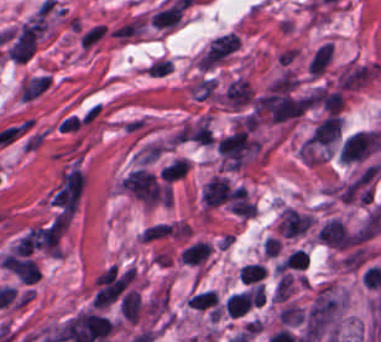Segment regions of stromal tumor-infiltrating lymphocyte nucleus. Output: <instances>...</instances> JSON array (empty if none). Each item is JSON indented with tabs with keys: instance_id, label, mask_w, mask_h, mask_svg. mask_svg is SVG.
<instances>
[{
	"instance_id": "stromal-tumor-infiltrating-lymphocyte-nucleus-1",
	"label": "stromal tumor-infiltrating lymphocyte nucleus",
	"mask_w": 381,
	"mask_h": 342,
	"mask_svg": "<svg viewBox=\"0 0 381 342\" xmlns=\"http://www.w3.org/2000/svg\"><path fill=\"white\" fill-rule=\"evenodd\" d=\"M224 99L233 109L248 106L253 99V88L243 77L233 79L224 91Z\"/></svg>"
},
{
	"instance_id": "stromal-tumor-infiltrating-lymphocyte-nucleus-2",
	"label": "stromal tumor-infiltrating lymphocyte nucleus",
	"mask_w": 381,
	"mask_h": 342,
	"mask_svg": "<svg viewBox=\"0 0 381 342\" xmlns=\"http://www.w3.org/2000/svg\"><path fill=\"white\" fill-rule=\"evenodd\" d=\"M231 188L227 177L214 175L202 191V199L207 207H216L227 201Z\"/></svg>"
},
{
	"instance_id": "stromal-tumor-infiltrating-lymphocyte-nucleus-3",
	"label": "stromal tumor-infiltrating lymphocyte nucleus",
	"mask_w": 381,
	"mask_h": 342,
	"mask_svg": "<svg viewBox=\"0 0 381 342\" xmlns=\"http://www.w3.org/2000/svg\"><path fill=\"white\" fill-rule=\"evenodd\" d=\"M119 311L125 319L135 324L140 311L139 292L131 289L126 293L119 304Z\"/></svg>"
},
{
	"instance_id": "stromal-tumor-infiltrating-lymphocyte-nucleus-4",
	"label": "stromal tumor-infiltrating lymphocyte nucleus",
	"mask_w": 381,
	"mask_h": 342,
	"mask_svg": "<svg viewBox=\"0 0 381 342\" xmlns=\"http://www.w3.org/2000/svg\"><path fill=\"white\" fill-rule=\"evenodd\" d=\"M210 249L207 242L196 241L184 248L180 258L185 264H201L208 256Z\"/></svg>"
},
{
	"instance_id": "stromal-tumor-infiltrating-lymphocyte-nucleus-5",
	"label": "stromal tumor-infiltrating lymphocyte nucleus",
	"mask_w": 381,
	"mask_h": 342,
	"mask_svg": "<svg viewBox=\"0 0 381 342\" xmlns=\"http://www.w3.org/2000/svg\"><path fill=\"white\" fill-rule=\"evenodd\" d=\"M334 48L331 44H324L310 61V75L319 76L328 67L333 57Z\"/></svg>"
},
{
	"instance_id": "stromal-tumor-infiltrating-lymphocyte-nucleus-6",
	"label": "stromal tumor-infiltrating lymphocyte nucleus",
	"mask_w": 381,
	"mask_h": 342,
	"mask_svg": "<svg viewBox=\"0 0 381 342\" xmlns=\"http://www.w3.org/2000/svg\"><path fill=\"white\" fill-rule=\"evenodd\" d=\"M189 166V159L184 157H176L160 169L159 175L163 180L171 182L177 178L184 176Z\"/></svg>"
},
{
	"instance_id": "stromal-tumor-infiltrating-lymphocyte-nucleus-7",
	"label": "stromal tumor-infiltrating lymphocyte nucleus",
	"mask_w": 381,
	"mask_h": 342,
	"mask_svg": "<svg viewBox=\"0 0 381 342\" xmlns=\"http://www.w3.org/2000/svg\"><path fill=\"white\" fill-rule=\"evenodd\" d=\"M196 310H205L218 303V294L212 289L194 293L186 302Z\"/></svg>"
},
{
	"instance_id": "stromal-tumor-infiltrating-lymphocyte-nucleus-8",
	"label": "stromal tumor-infiltrating lymphocyte nucleus",
	"mask_w": 381,
	"mask_h": 342,
	"mask_svg": "<svg viewBox=\"0 0 381 342\" xmlns=\"http://www.w3.org/2000/svg\"><path fill=\"white\" fill-rule=\"evenodd\" d=\"M266 272L264 265L259 263H246L240 268L238 278L249 284L264 278Z\"/></svg>"
}]
</instances>
